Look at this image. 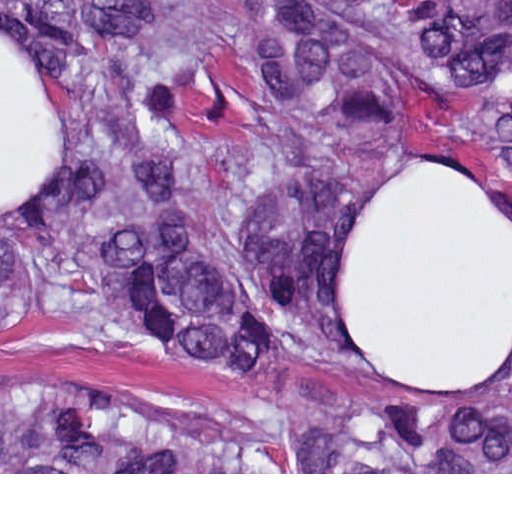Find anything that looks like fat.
Returning <instances> with one entry per match:
<instances>
[{"mask_svg": "<svg viewBox=\"0 0 512 512\" xmlns=\"http://www.w3.org/2000/svg\"><path fill=\"white\" fill-rule=\"evenodd\" d=\"M63 171V115L0 24V205ZM350 338L369 368L430 388H479L512 360V226L473 179L396 167L367 193L342 265Z\"/></svg>", "mask_w": 512, "mask_h": 512, "instance_id": "fat-1", "label": "fat"}]
</instances>
